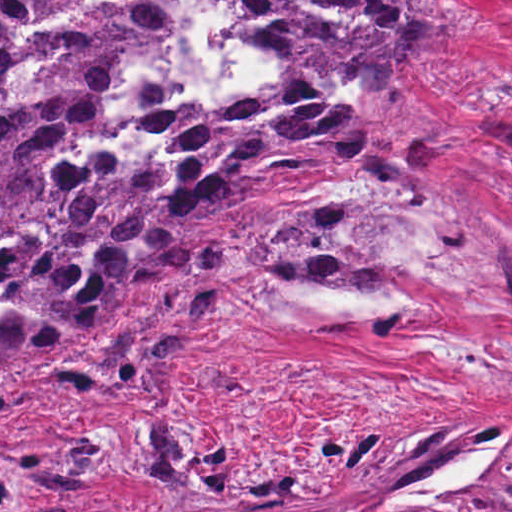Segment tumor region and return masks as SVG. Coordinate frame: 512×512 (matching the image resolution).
Listing matches in <instances>:
<instances>
[{
  "instance_id": "e687c5a6",
  "label": "tumor region",
  "mask_w": 512,
  "mask_h": 512,
  "mask_svg": "<svg viewBox=\"0 0 512 512\" xmlns=\"http://www.w3.org/2000/svg\"><path fill=\"white\" fill-rule=\"evenodd\" d=\"M228 38L261 55V81L206 109L178 97L167 59L183 31L170 0H0V405L4 361L78 346L32 375L156 389L200 321L267 278L369 287L384 274L339 230L348 214H266L204 247L245 180L312 170L396 172L442 127L402 95L470 25L451 0H216ZM100 429L0 430V502L65 494L103 473Z\"/></svg>"
}]
</instances>
